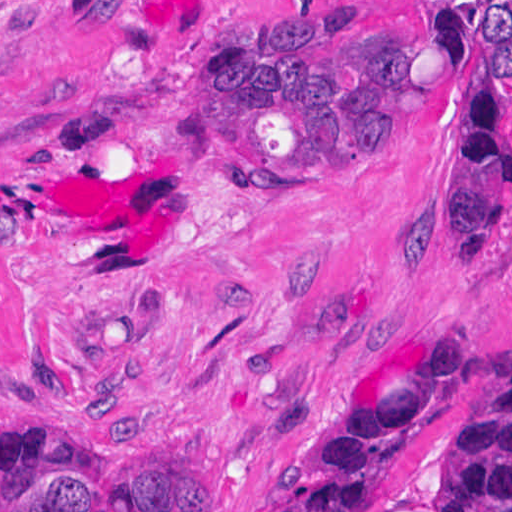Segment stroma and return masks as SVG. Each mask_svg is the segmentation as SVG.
Segmentation results:
<instances>
[{
    "instance_id": "obj_1",
    "label": "stroma",
    "mask_w": 512,
    "mask_h": 512,
    "mask_svg": "<svg viewBox=\"0 0 512 512\" xmlns=\"http://www.w3.org/2000/svg\"><path fill=\"white\" fill-rule=\"evenodd\" d=\"M270 1H441L325 180L227 173L207 126L213 62ZM468 1L512 0H0V427L158 457L193 512H278L446 335L469 370L369 512H447L512 368V201L443 232L469 154L456 104L493 98L512 138V75L467 56ZM93 389L119 410L79 406Z\"/></svg>"
}]
</instances>
